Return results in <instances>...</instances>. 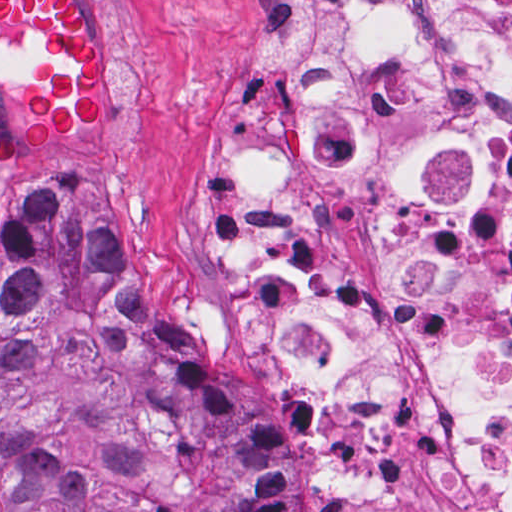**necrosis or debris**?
<instances>
[{
	"label": "necrosis or debris",
	"mask_w": 512,
	"mask_h": 512,
	"mask_svg": "<svg viewBox=\"0 0 512 512\" xmlns=\"http://www.w3.org/2000/svg\"><path fill=\"white\" fill-rule=\"evenodd\" d=\"M202 225L320 512H512V0H247Z\"/></svg>",
	"instance_id": "obj_1"
}]
</instances>
